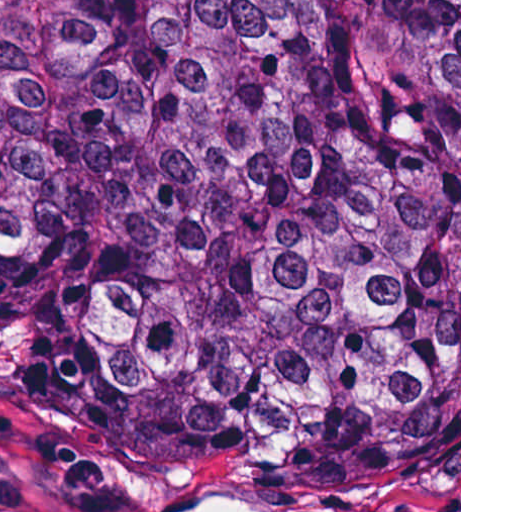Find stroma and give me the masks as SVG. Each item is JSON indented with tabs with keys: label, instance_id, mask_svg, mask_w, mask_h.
Returning a JSON list of instances; mask_svg holds the SVG:
<instances>
[{
	"label": "stroma",
	"instance_id": "35a3bbf8",
	"mask_svg": "<svg viewBox=\"0 0 512 512\" xmlns=\"http://www.w3.org/2000/svg\"><path fill=\"white\" fill-rule=\"evenodd\" d=\"M139 456L178 467L182 491L259 495L290 512H396L372 495L324 492L237 461L169 454L87 412L62 378L31 354V313L21 263L0 249V512H113L117 492L96 469L103 458ZM401 512H461V0H459V455L435 460Z\"/></svg>",
	"mask_w": 512,
	"mask_h": 512
}]
</instances>
